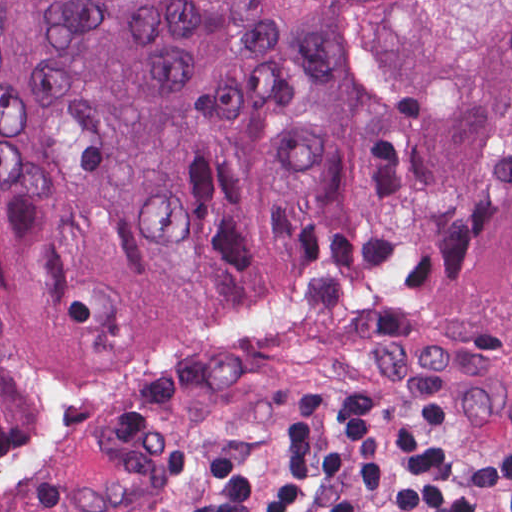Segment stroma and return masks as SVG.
<instances>
[{
  "instance_id": "obj_1",
  "label": "stroma",
  "mask_w": 512,
  "mask_h": 512,
  "mask_svg": "<svg viewBox=\"0 0 512 512\" xmlns=\"http://www.w3.org/2000/svg\"><path fill=\"white\" fill-rule=\"evenodd\" d=\"M320 43L350 82L408 108L512 89V0H333ZM286 410H455L512 428V341L384 304H292L36 373L0 449V512H177Z\"/></svg>"
}]
</instances>
